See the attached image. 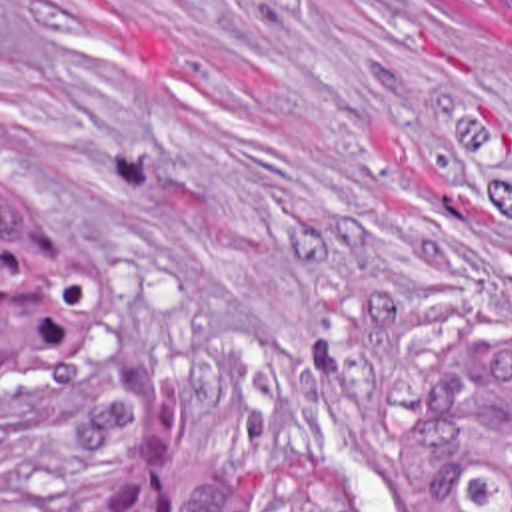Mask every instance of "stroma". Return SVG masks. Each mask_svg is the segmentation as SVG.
I'll return each instance as SVG.
<instances>
[{"label": "stroma", "mask_w": 512, "mask_h": 512, "mask_svg": "<svg viewBox=\"0 0 512 512\" xmlns=\"http://www.w3.org/2000/svg\"><path fill=\"white\" fill-rule=\"evenodd\" d=\"M0 199L102 277V327L0 387L52 512L124 443L174 507L254 461L434 512L420 375L512 335V18L498 0H0Z\"/></svg>", "instance_id": "stroma-1"}]
</instances>
